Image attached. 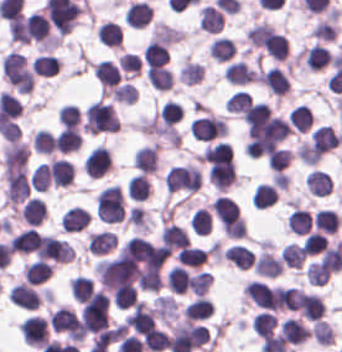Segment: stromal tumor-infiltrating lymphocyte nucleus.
<instances>
[{
	"instance_id": "obj_1",
	"label": "stromal tumor-infiltrating lymphocyte nucleus",
	"mask_w": 342,
	"mask_h": 352,
	"mask_svg": "<svg viewBox=\"0 0 342 352\" xmlns=\"http://www.w3.org/2000/svg\"><path fill=\"white\" fill-rule=\"evenodd\" d=\"M84 128L91 133L117 131V114L112 106L97 99L85 108Z\"/></svg>"
},
{
	"instance_id": "obj_2",
	"label": "stromal tumor-infiltrating lymphocyte nucleus",
	"mask_w": 342,
	"mask_h": 352,
	"mask_svg": "<svg viewBox=\"0 0 342 352\" xmlns=\"http://www.w3.org/2000/svg\"><path fill=\"white\" fill-rule=\"evenodd\" d=\"M4 194L7 206L14 210L28 199L30 190L25 167L7 164Z\"/></svg>"
},
{
	"instance_id": "obj_3",
	"label": "stromal tumor-infiltrating lymphocyte nucleus",
	"mask_w": 342,
	"mask_h": 352,
	"mask_svg": "<svg viewBox=\"0 0 342 352\" xmlns=\"http://www.w3.org/2000/svg\"><path fill=\"white\" fill-rule=\"evenodd\" d=\"M189 129L197 141H214L227 132L225 119L210 112L193 119Z\"/></svg>"
},
{
	"instance_id": "obj_4",
	"label": "stromal tumor-infiltrating lymphocyte nucleus",
	"mask_w": 342,
	"mask_h": 352,
	"mask_svg": "<svg viewBox=\"0 0 342 352\" xmlns=\"http://www.w3.org/2000/svg\"><path fill=\"white\" fill-rule=\"evenodd\" d=\"M51 329L70 341H82L79 322L73 310L62 306L49 313Z\"/></svg>"
},
{
	"instance_id": "obj_5",
	"label": "stromal tumor-infiltrating lymphocyte nucleus",
	"mask_w": 342,
	"mask_h": 352,
	"mask_svg": "<svg viewBox=\"0 0 342 352\" xmlns=\"http://www.w3.org/2000/svg\"><path fill=\"white\" fill-rule=\"evenodd\" d=\"M24 44H49L51 41L50 22L38 12H30L24 20Z\"/></svg>"
},
{
	"instance_id": "obj_6",
	"label": "stromal tumor-infiltrating lymphocyte nucleus",
	"mask_w": 342,
	"mask_h": 352,
	"mask_svg": "<svg viewBox=\"0 0 342 352\" xmlns=\"http://www.w3.org/2000/svg\"><path fill=\"white\" fill-rule=\"evenodd\" d=\"M23 339L35 348H43L49 339L48 319L38 314H30L19 325Z\"/></svg>"
},
{
	"instance_id": "obj_7",
	"label": "stromal tumor-infiltrating lymphocyte nucleus",
	"mask_w": 342,
	"mask_h": 352,
	"mask_svg": "<svg viewBox=\"0 0 342 352\" xmlns=\"http://www.w3.org/2000/svg\"><path fill=\"white\" fill-rule=\"evenodd\" d=\"M82 168L89 178H100L111 168V156L106 147L93 146L82 159Z\"/></svg>"
},
{
	"instance_id": "obj_8",
	"label": "stromal tumor-infiltrating lymphocyte nucleus",
	"mask_w": 342,
	"mask_h": 352,
	"mask_svg": "<svg viewBox=\"0 0 342 352\" xmlns=\"http://www.w3.org/2000/svg\"><path fill=\"white\" fill-rule=\"evenodd\" d=\"M123 323L133 332L143 334L154 328V311L144 302H137Z\"/></svg>"
},
{
	"instance_id": "obj_9",
	"label": "stromal tumor-infiltrating lymphocyte nucleus",
	"mask_w": 342,
	"mask_h": 352,
	"mask_svg": "<svg viewBox=\"0 0 342 352\" xmlns=\"http://www.w3.org/2000/svg\"><path fill=\"white\" fill-rule=\"evenodd\" d=\"M29 148L26 142L7 141L2 151L3 173L20 170L27 162Z\"/></svg>"
},
{
	"instance_id": "obj_10",
	"label": "stromal tumor-infiltrating lymphocyte nucleus",
	"mask_w": 342,
	"mask_h": 352,
	"mask_svg": "<svg viewBox=\"0 0 342 352\" xmlns=\"http://www.w3.org/2000/svg\"><path fill=\"white\" fill-rule=\"evenodd\" d=\"M259 82L273 95H287L291 89L286 73L279 66H271L260 71Z\"/></svg>"
},
{
	"instance_id": "obj_11",
	"label": "stromal tumor-infiltrating lymphocyte nucleus",
	"mask_w": 342,
	"mask_h": 352,
	"mask_svg": "<svg viewBox=\"0 0 342 352\" xmlns=\"http://www.w3.org/2000/svg\"><path fill=\"white\" fill-rule=\"evenodd\" d=\"M244 292L256 306L277 310L272 288L265 281L254 278L244 285Z\"/></svg>"
},
{
	"instance_id": "obj_12",
	"label": "stromal tumor-infiltrating lymphocyte nucleus",
	"mask_w": 342,
	"mask_h": 352,
	"mask_svg": "<svg viewBox=\"0 0 342 352\" xmlns=\"http://www.w3.org/2000/svg\"><path fill=\"white\" fill-rule=\"evenodd\" d=\"M153 10L147 1H133L125 11L123 22L133 29H142L149 24Z\"/></svg>"
},
{
	"instance_id": "obj_13",
	"label": "stromal tumor-infiltrating lymphocyte nucleus",
	"mask_w": 342,
	"mask_h": 352,
	"mask_svg": "<svg viewBox=\"0 0 342 352\" xmlns=\"http://www.w3.org/2000/svg\"><path fill=\"white\" fill-rule=\"evenodd\" d=\"M333 55L325 45L312 44L302 48L301 58L309 71H316L330 64Z\"/></svg>"
},
{
	"instance_id": "obj_14",
	"label": "stromal tumor-infiltrating lymphocyte nucleus",
	"mask_w": 342,
	"mask_h": 352,
	"mask_svg": "<svg viewBox=\"0 0 342 352\" xmlns=\"http://www.w3.org/2000/svg\"><path fill=\"white\" fill-rule=\"evenodd\" d=\"M252 264L257 275L276 277L281 272L284 262L262 246Z\"/></svg>"
},
{
	"instance_id": "obj_15",
	"label": "stromal tumor-infiltrating lymphocyte nucleus",
	"mask_w": 342,
	"mask_h": 352,
	"mask_svg": "<svg viewBox=\"0 0 342 352\" xmlns=\"http://www.w3.org/2000/svg\"><path fill=\"white\" fill-rule=\"evenodd\" d=\"M223 76L230 83L243 86L256 82L257 70L237 60L226 65Z\"/></svg>"
},
{
	"instance_id": "obj_16",
	"label": "stromal tumor-infiltrating lymphocyte nucleus",
	"mask_w": 342,
	"mask_h": 352,
	"mask_svg": "<svg viewBox=\"0 0 342 352\" xmlns=\"http://www.w3.org/2000/svg\"><path fill=\"white\" fill-rule=\"evenodd\" d=\"M8 298L18 307L38 308L40 297L33 287L25 282H20L11 287Z\"/></svg>"
},
{
	"instance_id": "obj_17",
	"label": "stromal tumor-infiltrating lymphocyte nucleus",
	"mask_w": 342,
	"mask_h": 352,
	"mask_svg": "<svg viewBox=\"0 0 342 352\" xmlns=\"http://www.w3.org/2000/svg\"><path fill=\"white\" fill-rule=\"evenodd\" d=\"M91 216L83 207L72 206L61 217L63 231L77 232L86 229Z\"/></svg>"
},
{
	"instance_id": "obj_18",
	"label": "stromal tumor-infiltrating lymphocyte nucleus",
	"mask_w": 342,
	"mask_h": 352,
	"mask_svg": "<svg viewBox=\"0 0 342 352\" xmlns=\"http://www.w3.org/2000/svg\"><path fill=\"white\" fill-rule=\"evenodd\" d=\"M117 238L112 231H99L87 235V250L97 256H105L116 247Z\"/></svg>"
},
{
	"instance_id": "obj_19",
	"label": "stromal tumor-infiltrating lymphocyte nucleus",
	"mask_w": 342,
	"mask_h": 352,
	"mask_svg": "<svg viewBox=\"0 0 342 352\" xmlns=\"http://www.w3.org/2000/svg\"><path fill=\"white\" fill-rule=\"evenodd\" d=\"M53 267L49 261L32 260L23 265L22 271L28 283L41 284L49 280Z\"/></svg>"
},
{
	"instance_id": "obj_20",
	"label": "stromal tumor-infiltrating lymphocyte nucleus",
	"mask_w": 342,
	"mask_h": 352,
	"mask_svg": "<svg viewBox=\"0 0 342 352\" xmlns=\"http://www.w3.org/2000/svg\"><path fill=\"white\" fill-rule=\"evenodd\" d=\"M74 176V168L66 158H53L50 161V181L54 186H67Z\"/></svg>"
},
{
	"instance_id": "obj_21",
	"label": "stromal tumor-infiltrating lymphocyte nucleus",
	"mask_w": 342,
	"mask_h": 352,
	"mask_svg": "<svg viewBox=\"0 0 342 352\" xmlns=\"http://www.w3.org/2000/svg\"><path fill=\"white\" fill-rule=\"evenodd\" d=\"M152 191V183L144 173H137L126 183L128 199L132 201H144L148 199Z\"/></svg>"
},
{
	"instance_id": "obj_22",
	"label": "stromal tumor-infiltrating lymphocyte nucleus",
	"mask_w": 342,
	"mask_h": 352,
	"mask_svg": "<svg viewBox=\"0 0 342 352\" xmlns=\"http://www.w3.org/2000/svg\"><path fill=\"white\" fill-rule=\"evenodd\" d=\"M170 56L168 45L151 38L148 40L142 52V60L149 65H163Z\"/></svg>"
},
{
	"instance_id": "obj_23",
	"label": "stromal tumor-infiltrating lymphocyte nucleus",
	"mask_w": 342,
	"mask_h": 352,
	"mask_svg": "<svg viewBox=\"0 0 342 352\" xmlns=\"http://www.w3.org/2000/svg\"><path fill=\"white\" fill-rule=\"evenodd\" d=\"M161 241L171 255L189 242L185 230L170 223L163 225Z\"/></svg>"
},
{
	"instance_id": "obj_24",
	"label": "stromal tumor-infiltrating lymphocyte nucleus",
	"mask_w": 342,
	"mask_h": 352,
	"mask_svg": "<svg viewBox=\"0 0 342 352\" xmlns=\"http://www.w3.org/2000/svg\"><path fill=\"white\" fill-rule=\"evenodd\" d=\"M304 184L308 193L322 196L333 186L330 176L325 171L315 168L304 176Z\"/></svg>"
},
{
	"instance_id": "obj_25",
	"label": "stromal tumor-infiltrating lymphocyte nucleus",
	"mask_w": 342,
	"mask_h": 352,
	"mask_svg": "<svg viewBox=\"0 0 342 352\" xmlns=\"http://www.w3.org/2000/svg\"><path fill=\"white\" fill-rule=\"evenodd\" d=\"M158 146L153 144L138 148L135 153V166L144 173L157 172Z\"/></svg>"
},
{
	"instance_id": "obj_26",
	"label": "stromal tumor-infiltrating lymphocyte nucleus",
	"mask_w": 342,
	"mask_h": 352,
	"mask_svg": "<svg viewBox=\"0 0 342 352\" xmlns=\"http://www.w3.org/2000/svg\"><path fill=\"white\" fill-rule=\"evenodd\" d=\"M20 219L27 225L39 226L46 219L44 203L38 198H30L20 211Z\"/></svg>"
},
{
	"instance_id": "obj_27",
	"label": "stromal tumor-infiltrating lymphocyte nucleus",
	"mask_w": 342,
	"mask_h": 352,
	"mask_svg": "<svg viewBox=\"0 0 342 352\" xmlns=\"http://www.w3.org/2000/svg\"><path fill=\"white\" fill-rule=\"evenodd\" d=\"M94 72L99 84L105 87L117 85L121 77V70L114 63L105 59L96 61Z\"/></svg>"
},
{
	"instance_id": "obj_28",
	"label": "stromal tumor-infiltrating lymphocyte nucleus",
	"mask_w": 342,
	"mask_h": 352,
	"mask_svg": "<svg viewBox=\"0 0 342 352\" xmlns=\"http://www.w3.org/2000/svg\"><path fill=\"white\" fill-rule=\"evenodd\" d=\"M312 222L318 230L334 235L340 226L341 218L336 210L323 208L316 211Z\"/></svg>"
},
{
	"instance_id": "obj_29",
	"label": "stromal tumor-infiltrating lymphocyte nucleus",
	"mask_w": 342,
	"mask_h": 352,
	"mask_svg": "<svg viewBox=\"0 0 342 352\" xmlns=\"http://www.w3.org/2000/svg\"><path fill=\"white\" fill-rule=\"evenodd\" d=\"M146 76L149 84L161 91H168L174 80L172 70L163 65L152 66L146 70Z\"/></svg>"
},
{
	"instance_id": "obj_30",
	"label": "stromal tumor-infiltrating lymphocyte nucleus",
	"mask_w": 342,
	"mask_h": 352,
	"mask_svg": "<svg viewBox=\"0 0 342 352\" xmlns=\"http://www.w3.org/2000/svg\"><path fill=\"white\" fill-rule=\"evenodd\" d=\"M214 306L204 296H197L188 302L184 307V314L193 321L207 319L213 310Z\"/></svg>"
},
{
	"instance_id": "obj_31",
	"label": "stromal tumor-infiltrating lymphocyte nucleus",
	"mask_w": 342,
	"mask_h": 352,
	"mask_svg": "<svg viewBox=\"0 0 342 352\" xmlns=\"http://www.w3.org/2000/svg\"><path fill=\"white\" fill-rule=\"evenodd\" d=\"M35 76L52 77L57 74L60 67L59 59L51 54H38L31 63Z\"/></svg>"
},
{
	"instance_id": "obj_32",
	"label": "stromal tumor-infiltrating lymphocyte nucleus",
	"mask_w": 342,
	"mask_h": 352,
	"mask_svg": "<svg viewBox=\"0 0 342 352\" xmlns=\"http://www.w3.org/2000/svg\"><path fill=\"white\" fill-rule=\"evenodd\" d=\"M311 225L312 218L308 209L295 207L286 219L288 230L295 234H308Z\"/></svg>"
},
{
	"instance_id": "obj_33",
	"label": "stromal tumor-infiltrating lymphocyte nucleus",
	"mask_w": 342,
	"mask_h": 352,
	"mask_svg": "<svg viewBox=\"0 0 342 352\" xmlns=\"http://www.w3.org/2000/svg\"><path fill=\"white\" fill-rule=\"evenodd\" d=\"M178 263L190 267H201L207 254L204 247L198 245H184L175 255Z\"/></svg>"
},
{
	"instance_id": "obj_34",
	"label": "stromal tumor-infiltrating lymphocyte nucleus",
	"mask_w": 342,
	"mask_h": 352,
	"mask_svg": "<svg viewBox=\"0 0 342 352\" xmlns=\"http://www.w3.org/2000/svg\"><path fill=\"white\" fill-rule=\"evenodd\" d=\"M39 233L32 229H24L14 235L10 240V244L14 252L31 254L35 250Z\"/></svg>"
},
{
	"instance_id": "obj_35",
	"label": "stromal tumor-infiltrating lymphocyte nucleus",
	"mask_w": 342,
	"mask_h": 352,
	"mask_svg": "<svg viewBox=\"0 0 342 352\" xmlns=\"http://www.w3.org/2000/svg\"><path fill=\"white\" fill-rule=\"evenodd\" d=\"M96 36L101 43L107 46L120 47L122 40V29L112 21H105L98 25Z\"/></svg>"
},
{
	"instance_id": "obj_36",
	"label": "stromal tumor-infiltrating lymphocyte nucleus",
	"mask_w": 342,
	"mask_h": 352,
	"mask_svg": "<svg viewBox=\"0 0 342 352\" xmlns=\"http://www.w3.org/2000/svg\"><path fill=\"white\" fill-rule=\"evenodd\" d=\"M236 51V44L230 37L218 36L212 42L209 48L211 58L218 61L229 60Z\"/></svg>"
},
{
	"instance_id": "obj_37",
	"label": "stromal tumor-infiltrating lymphocyte nucleus",
	"mask_w": 342,
	"mask_h": 352,
	"mask_svg": "<svg viewBox=\"0 0 342 352\" xmlns=\"http://www.w3.org/2000/svg\"><path fill=\"white\" fill-rule=\"evenodd\" d=\"M111 300L118 309L132 307L137 300L136 288L131 283H123L111 292Z\"/></svg>"
},
{
	"instance_id": "obj_38",
	"label": "stromal tumor-infiltrating lymphocyte nucleus",
	"mask_w": 342,
	"mask_h": 352,
	"mask_svg": "<svg viewBox=\"0 0 342 352\" xmlns=\"http://www.w3.org/2000/svg\"><path fill=\"white\" fill-rule=\"evenodd\" d=\"M166 282L169 289L184 294L189 289V271L181 265H174L167 274Z\"/></svg>"
},
{
	"instance_id": "obj_39",
	"label": "stromal tumor-infiltrating lymphocyte nucleus",
	"mask_w": 342,
	"mask_h": 352,
	"mask_svg": "<svg viewBox=\"0 0 342 352\" xmlns=\"http://www.w3.org/2000/svg\"><path fill=\"white\" fill-rule=\"evenodd\" d=\"M82 143L81 133L74 128H66L59 132L56 140V151L70 153L77 150Z\"/></svg>"
},
{
	"instance_id": "obj_40",
	"label": "stromal tumor-infiltrating lymphocyte nucleus",
	"mask_w": 342,
	"mask_h": 352,
	"mask_svg": "<svg viewBox=\"0 0 342 352\" xmlns=\"http://www.w3.org/2000/svg\"><path fill=\"white\" fill-rule=\"evenodd\" d=\"M277 192L275 188L268 183L257 184L252 197L251 202L254 208H267L275 202L277 199Z\"/></svg>"
},
{
	"instance_id": "obj_41",
	"label": "stromal tumor-infiltrating lymphocyte nucleus",
	"mask_w": 342,
	"mask_h": 352,
	"mask_svg": "<svg viewBox=\"0 0 342 352\" xmlns=\"http://www.w3.org/2000/svg\"><path fill=\"white\" fill-rule=\"evenodd\" d=\"M253 98L250 92L235 90L227 99L225 103V110L239 116H244Z\"/></svg>"
},
{
	"instance_id": "obj_42",
	"label": "stromal tumor-infiltrating lymphocyte nucleus",
	"mask_w": 342,
	"mask_h": 352,
	"mask_svg": "<svg viewBox=\"0 0 342 352\" xmlns=\"http://www.w3.org/2000/svg\"><path fill=\"white\" fill-rule=\"evenodd\" d=\"M287 118L292 128L298 132H305L313 120V116L305 104H298L293 107Z\"/></svg>"
},
{
	"instance_id": "obj_43",
	"label": "stromal tumor-infiltrating lymphocyte nucleus",
	"mask_w": 342,
	"mask_h": 352,
	"mask_svg": "<svg viewBox=\"0 0 342 352\" xmlns=\"http://www.w3.org/2000/svg\"><path fill=\"white\" fill-rule=\"evenodd\" d=\"M204 74V65L185 60L178 70V80L184 84H198Z\"/></svg>"
},
{
	"instance_id": "obj_44",
	"label": "stromal tumor-infiltrating lymphocyte nucleus",
	"mask_w": 342,
	"mask_h": 352,
	"mask_svg": "<svg viewBox=\"0 0 342 352\" xmlns=\"http://www.w3.org/2000/svg\"><path fill=\"white\" fill-rule=\"evenodd\" d=\"M293 309L304 315L312 322L324 314L323 300L317 293Z\"/></svg>"
},
{
	"instance_id": "obj_45",
	"label": "stromal tumor-infiltrating lymphocyte nucleus",
	"mask_w": 342,
	"mask_h": 352,
	"mask_svg": "<svg viewBox=\"0 0 342 352\" xmlns=\"http://www.w3.org/2000/svg\"><path fill=\"white\" fill-rule=\"evenodd\" d=\"M190 229L197 234H210L211 229V215L207 207H200L195 209L192 218L189 222Z\"/></svg>"
},
{
	"instance_id": "obj_46",
	"label": "stromal tumor-infiltrating lymphocyte nucleus",
	"mask_w": 342,
	"mask_h": 352,
	"mask_svg": "<svg viewBox=\"0 0 342 352\" xmlns=\"http://www.w3.org/2000/svg\"><path fill=\"white\" fill-rule=\"evenodd\" d=\"M281 260L292 267H301L304 263L305 250L300 244L287 243L280 251Z\"/></svg>"
},
{
	"instance_id": "obj_47",
	"label": "stromal tumor-infiltrating lymphocyte nucleus",
	"mask_w": 342,
	"mask_h": 352,
	"mask_svg": "<svg viewBox=\"0 0 342 352\" xmlns=\"http://www.w3.org/2000/svg\"><path fill=\"white\" fill-rule=\"evenodd\" d=\"M111 97L115 102L132 105L137 100V90L131 81H123L113 87Z\"/></svg>"
},
{
	"instance_id": "obj_48",
	"label": "stromal tumor-infiltrating lymphocyte nucleus",
	"mask_w": 342,
	"mask_h": 352,
	"mask_svg": "<svg viewBox=\"0 0 342 352\" xmlns=\"http://www.w3.org/2000/svg\"><path fill=\"white\" fill-rule=\"evenodd\" d=\"M29 184L33 190L46 191L50 186V168L46 163H39L30 174Z\"/></svg>"
},
{
	"instance_id": "obj_49",
	"label": "stromal tumor-infiltrating lymphocyte nucleus",
	"mask_w": 342,
	"mask_h": 352,
	"mask_svg": "<svg viewBox=\"0 0 342 352\" xmlns=\"http://www.w3.org/2000/svg\"><path fill=\"white\" fill-rule=\"evenodd\" d=\"M82 122V110L76 104H63L60 106V123L65 127L79 128Z\"/></svg>"
},
{
	"instance_id": "obj_50",
	"label": "stromal tumor-infiltrating lymphocyte nucleus",
	"mask_w": 342,
	"mask_h": 352,
	"mask_svg": "<svg viewBox=\"0 0 342 352\" xmlns=\"http://www.w3.org/2000/svg\"><path fill=\"white\" fill-rule=\"evenodd\" d=\"M32 145L38 153L51 154L55 151V139L50 131L38 130L33 133Z\"/></svg>"
},
{
	"instance_id": "obj_51",
	"label": "stromal tumor-infiltrating lymphocyte nucleus",
	"mask_w": 342,
	"mask_h": 352,
	"mask_svg": "<svg viewBox=\"0 0 342 352\" xmlns=\"http://www.w3.org/2000/svg\"><path fill=\"white\" fill-rule=\"evenodd\" d=\"M293 158V152L284 147H277L268 157L267 164L273 170L283 171Z\"/></svg>"
},
{
	"instance_id": "obj_52",
	"label": "stromal tumor-infiltrating lymphocyte nucleus",
	"mask_w": 342,
	"mask_h": 352,
	"mask_svg": "<svg viewBox=\"0 0 342 352\" xmlns=\"http://www.w3.org/2000/svg\"><path fill=\"white\" fill-rule=\"evenodd\" d=\"M211 283L212 276L210 275V273L201 270L195 272L189 278V288L198 296L207 293Z\"/></svg>"
},
{
	"instance_id": "obj_53",
	"label": "stromal tumor-infiltrating lymphocyte nucleus",
	"mask_w": 342,
	"mask_h": 352,
	"mask_svg": "<svg viewBox=\"0 0 342 352\" xmlns=\"http://www.w3.org/2000/svg\"><path fill=\"white\" fill-rule=\"evenodd\" d=\"M328 246V240L324 233L311 231L307 236L304 249L307 255H315Z\"/></svg>"
},
{
	"instance_id": "obj_54",
	"label": "stromal tumor-infiltrating lymphocyte nucleus",
	"mask_w": 342,
	"mask_h": 352,
	"mask_svg": "<svg viewBox=\"0 0 342 352\" xmlns=\"http://www.w3.org/2000/svg\"><path fill=\"white\" fill-rule=\"evenodd\" d=\"M165 333L158 329H152L145 334L143 340L144 349L153 352H160L164 349Z\"/></svg>"
},
{
	"instance_id": "obj_55",
	"label": "stromal tumor-infiltrating lymphocyte nucleus",
	"mask_w": 342,
	"mask_h": 352,
	"mask_svg": "<svg viewBox=\"0 0 342 352\" xmlns=\"http://www.w3.org/2000/svg\"><path fill=\"white\" fill-rule=\"evenodd\" d=\"M118 60L123 71L129 72L136 76L141 74L142 65L140 57L136 53H122Z\"/></svg>"
},
{
	"instance_id": "obj_56",
	"label": "stromal tumor-infiltrating lymphocyte nucleus",
	"mask_w": 342,
	"mask_h": 352,
	"mask_svg": "<svg viewBox=\"0 0 342 352\" xmlns=\"http://www.w3.org/2000/svg\"><path fill=\"white\" fill-rule=\"evenodd\" d=\"M92 284V278L83 275H76L74 283V293L78 303L89 290V288L92 286Z\"/></svg>"
}]
</instances>
